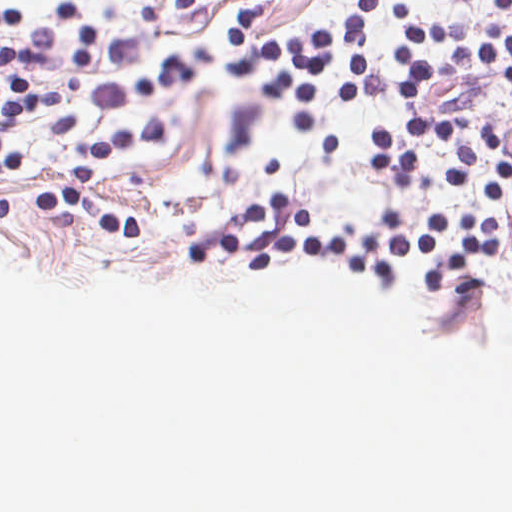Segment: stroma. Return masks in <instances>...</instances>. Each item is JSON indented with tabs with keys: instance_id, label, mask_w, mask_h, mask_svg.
<instances>
[{
	"instance_id": "35a3bbf8",
	"label": "stroma",
	"mask_w": 512,
	"mask_h": 512,
	"mask_svg": "<svg viewBox=\"0 0 512 512\" xmlns=\"http://www.w3.org/2000/svg\"><path fill=\"white\" fill-rule=\"evenodd\" d=\"M107 30L265 80L252 58L227 44L224 19L237 3L248 5L247 39L307 35L346 21L357 0H19ZM422 21L455 23L500 14L498 0H398ZM512 35V9L506 13ZM400 32L396 0H373L363 34L367 97L343 105L391 122L416 114L461 118L474 138L487 124L512 132V80L506 75L445 77L427 84L418 101H404L394 78L408 65L390 48Z\"/></svg>"
}]
</instances>
